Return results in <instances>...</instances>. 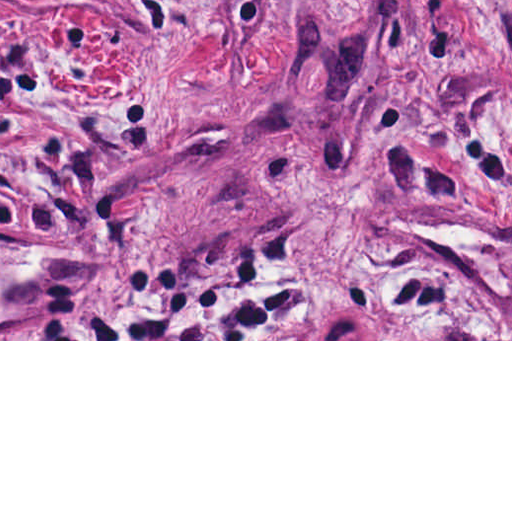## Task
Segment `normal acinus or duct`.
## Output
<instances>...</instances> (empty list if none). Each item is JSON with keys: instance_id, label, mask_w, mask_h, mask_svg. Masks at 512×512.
Listing matches in <instances>:
<instances>
[{"instance_id": "30e58d81", "label": "normal acinus or duct", "mask_w": 512, "mask_h": 512, "mask_svg": "<svg viewBox=\"0 0 512 512\" xmlns=\"http://www.w3.org/2000/svg\"><path fill=\"white\" fill-rule=\"evenodd\" d=\"M318 339H375V333L359 317H340L327 324ZM437 339H472V329L447 331Z\"/></svg>"}]
</instances>
